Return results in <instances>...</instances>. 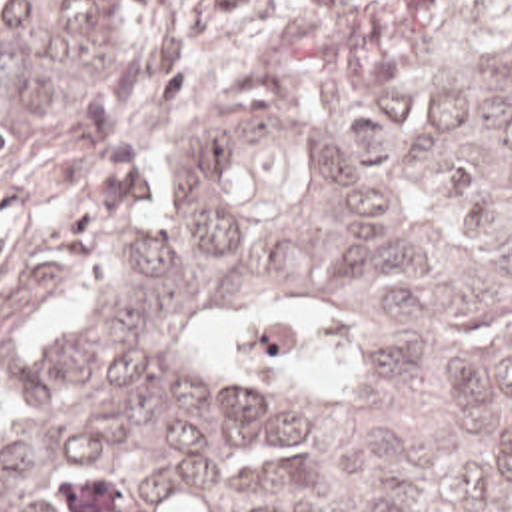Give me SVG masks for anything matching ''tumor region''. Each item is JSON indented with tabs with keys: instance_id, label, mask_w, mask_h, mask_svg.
Segmentation results:
<instances>
[{
	"instance_id": "1",
	"label": "tumor region",
	"mask_w": 512,
	"mask_h": 512,
	"mask_svg": "<svg viewBox=\"0 0 512 512\" xmlns=\"http://www.w3.org/2000/svg\"><path fill=\"white\" fill-rule=\"evenodd\" d=\"M140 59L0 0V173ZM0 512H512V0H320L0 383Z\"/></svg>"
}]
</instances>
